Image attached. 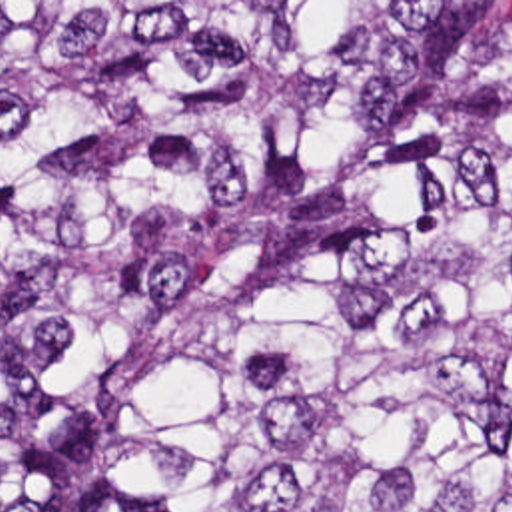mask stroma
<instances>
[{
	"label": "stroma",
	"instance_id": "obj_1",
	"mask_svg": "<svg viewBox=\"0 0 512 512\" xmlns=\"http://www.w3.org/2000/svg\"><path fill=\"white\" fill-rule=\"evenodd\" d=\"M0 2H512V0H0ZM0 512H15L0 479Z\"/></svg>",
	"mask_w": 512,
	"mask_h": 512
}]
</instances>
